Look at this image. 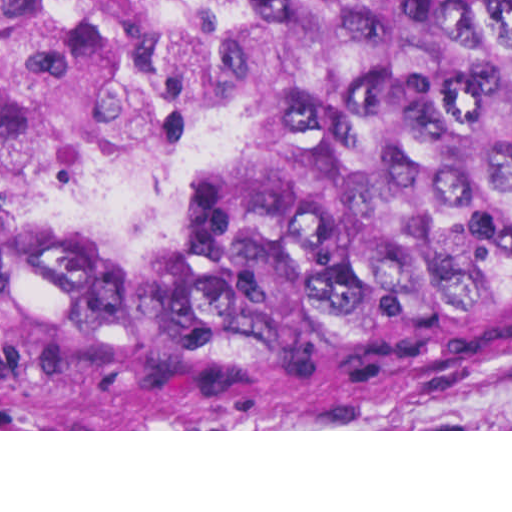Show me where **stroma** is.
<instances>
[{
    "label": "stroma",
    "mask_w": 512,
    "mask_h": 512,
    "mask_svg": "<svg viewBox=\"0 0 512 512\" xmlns=\"http://www.w3.org/2000/svg\"><path fill=\"white\" fill-rule=\"evenodd\" d=\"M190 34L208 51L226 98V154L172 208L125 217L36 202L16 164V134L0 114V142L9 147L4 203L9 226L61 220L86 236H150L178 227L189 200L208 182L263 158V126L232 86V0H183ZM0 431H512V382L458 397L410 418H359L338 423H260L230 429H57L0 412Z\"/></svg>",
    "instance_id": "1"
}]
</instances>
